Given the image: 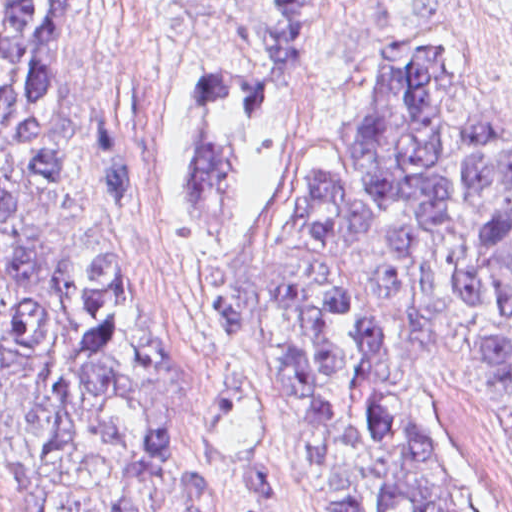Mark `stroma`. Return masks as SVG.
I'll use <instances>...</instances> for the list:
<instances>
[{
	"label": "stroma",
	"mask_w": 512,
	"mask_h": 512,
	"mask_svg": "<svg viewBox=\"0 0 512 512\" xmlns=\"http://www.w3.org/2000/svg\"><path fill=\"white\" fill-rule=\"evenodd\" d=\"M473 39H487L497 55L512 114V15L494 0H354L335 17L255 150L244 232L230 246L249 322L225 340L194 327L182 300L207 222L191 213L165 40L144 0H91L68 27L58 90L83 169L58 211L62 244L143 266L151 301L188 362L198 438L260 512H318L275 337L265 234L303 169L388 116L409 55ZM104 168L127 203L114 205ZM406 418L470 512H512L510 397L441 367L419 374ZM0 512H25L22 469L1 422Z\"/></svg>",
	"instance_id": "obj_1"
}]
</instances>
